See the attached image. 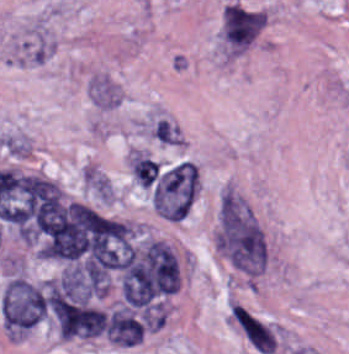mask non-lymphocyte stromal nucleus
<instances>
[{
    "label": "non-lymphocyte stromal nucleus",
    "mask_w": 349,
    "mask_h": 354,
    "mask_svg": "<svg viewBox=\"0 0 349 354\" xmlns=\"http://www.w3.org/2000/svg\"><path fill=\"white\" fill-rule=\"evenodd\" d=\"M179 136V131L175 128V126L170 122L169 125L166 127L164 132L161 134V136L158 138L159 143H164V144H174L176 139Z\"/></svg>",
    "instance_id": "81446118"
},
{
    "label": "non-lymphocyte stromal nucleus",
    "mask_w": 349,
    "mask_h": 354,
    "mask_svg": "<svg viewBox=\"0 0 349 354\" xmlns=\"http://www.w3.org/2000/svg\"><path fill=\"white\" fill-rule=\"evenodd\" d=\"M197 174L194 163L180 160L163 173L154 185L151 202L156 212L179 220L184 217L196 193Z\"/></svg>",
    "instance_id": "a72fc3eb"
},
{
    "label": "non-lymphocyte stromal nucleus",
    "mask_w": 349,
    "mask_h": 354,
    "mask_svg": "<svg viewBox=\"0 0 349 354\" xmlns=\"http://www.w3.org/2000/svg\"><path fill=\"white\" fill-rule=\"evenodd\" d=\"M227 316L230 325L255 352L271 354L280 347L277 327L239 300L228 304Z\"/></svg>",
    "instance_id": "3746e769"
},
{
    "label": "non-lymphocyte stromal nucleus",
    "mask_w": 349,
    "mask_h": 354,
    "mask_svg": "<svg viewBox=\"0 0 349 354\" xmlns=\"http://www.w3.org/2000/svg\"><path fill=\"white\" fill-rule=\"evenodd\" d=\"M217 246L227 261L244 273L255 275L264 269V235L251 209L240 201H221Z\"/></svg>",
    "instance_id": "dd21d789"
},
{
    "label": "non-lymphocyte stromal nucleus",
    "mask_w": 349,
    "mask_h": 354,
    "mask_svg": "<svg viewBox=\"0 0 349 354\" xmlns=\"http://www.w3.org/2000/svg\"><path fill=\"white\" fill-rule=\"evenodd\" d=\"M130 168L134 178L142 185H149L158 175L157 163L138 152H131Z\"/></svg>",
    "instance_id": "fc2b8d12"
}]
</instances>
